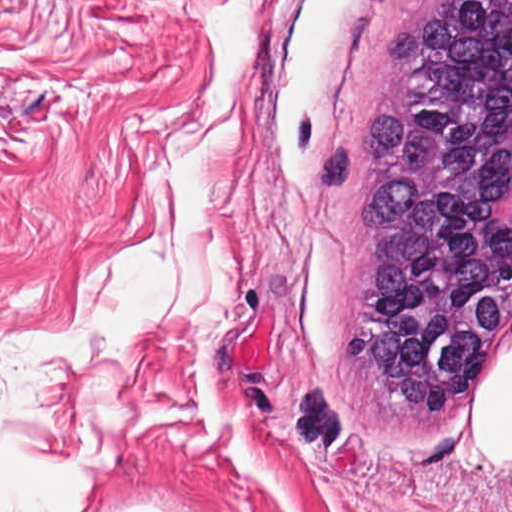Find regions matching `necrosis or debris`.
Instances as JSON below:
<instances>
[{"label": "necrosis or debris", "instance_id": "obj_1", "mask_svg": "<svg viewBox=\"0 0 512 512\" xmlns=\"http://www.w3.org/2000/svg\"><path fill=\"white\" fill-rule=\"evenodd\" d=\"M499 215L507 219L512 218V166L508 170L502 185Z\"/></svg>", "mask_w": 512, "mask_h": 512}]
</instances>
